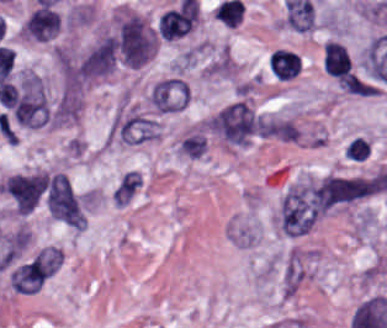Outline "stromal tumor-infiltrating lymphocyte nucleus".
<instances>
[{"instance_id":"1","label":"stromal tumor-infiltrating lymphocyte nucleus","mask_w":387,"mask_h":328,"mask_svg":"<svg viewBox=\"0 0 387 328\" xmlns=\"http://www.w3.org/2000/svg\"><path fill=\"white\" fill-rule=\"evenodd\" d=\"M25 36L38 42H50L61 29L60 12L51 5H38L24 20Z\"/></svg>"},{"instance_id":"2","label":"stromal tumor-infiltrating lymphocyte nucleus","mask_w":387,"mask_h":328,"mask_svg":"<svg viewBox=\"0 0 387 328\" xmlns=\"http://www.w3.org/2000/svg\"><path fill=\"white\" fill-rule=\"evenodd\" d=\"M193 23V7H171L159 17L157 28L162 37L174 40L182 37Z\"/></svg>"},{"instance_id":"3","label":"stromal tumor-infiltrating lymphocyte nucleus","mask_w":387,"mask_h":328,"mask_svg":"<svg viewBox=\"0 0 387 328\" xmlns=\"http://www.w3.org/2000/svg\"><path fill=\"white\" fill-rule=\"evenodd\" d=\"M268 67L273 78L281 81L294 79L302 69L299 54L289 48H276L268 59Z\"/></svg>"}]
</instances>
